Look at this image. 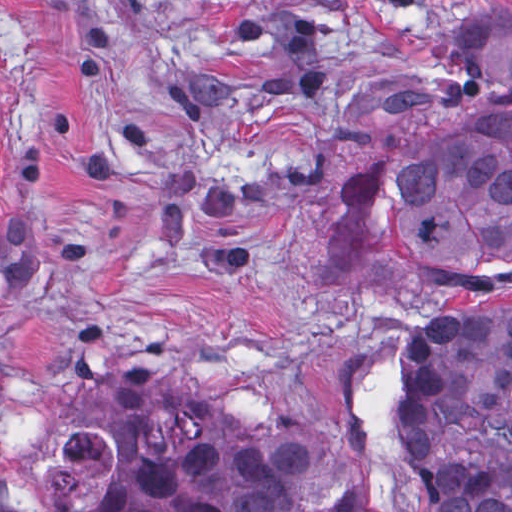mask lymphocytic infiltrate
I'll list each match as a JSON object with an SVG mask.
<instances>
[{"instance_id": "f902f5d3", "label": "lymphocytic infiltrate", "mask_w": 512, "mask_h": 512, "mask_svg": "<svg viewBox=\"0 0 512 512\" xmlns=\"http://www.w3.org/2000/svg\"><path fill=\"white\" fill-rule=\"evenodd\" d=\"M389 8H413L415 0H373Z\"/></svg>"}]
</instances>
